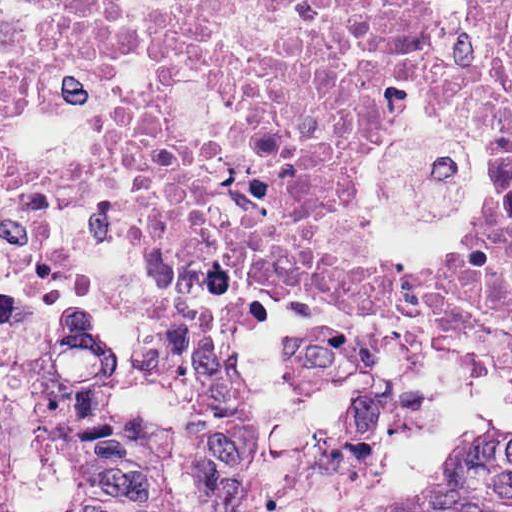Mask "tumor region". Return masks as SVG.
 I'll use <instances>...</instances> for the list:
<instances>
[{
	"mask_svg": "<svg viewBox=\"0 0 512 512\" xmlns=\"http://www.w3.org/2000/svg\"><path fill=\"white\" fill-rule=\"evenodd\" d=\"M129 356L103 309L60 314L0 371V460L129 403Z\"/></svg>",
	"mask_w": 512,
	"mask_h": 512,
	"instance_id": "obj_1",
	"label": "tumor region"
}]
</instances>
